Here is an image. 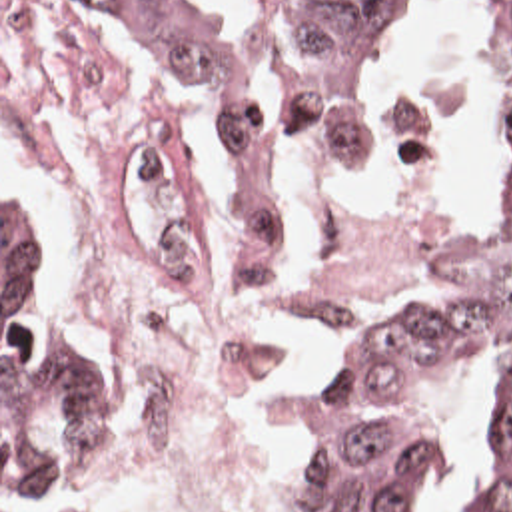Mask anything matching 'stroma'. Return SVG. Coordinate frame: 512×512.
<instances>
[{
    "label": "stroma",
    "instance_id": "1",
    "mask_svg": "<svg viewBox=\"0 0 512 512\" xmlns=\"http://www.w3.org/2000/svg\"><path fill=\"white\" fill-rule=\"evenodd\" d=\"M94 21L118 47L132 77L166 109L178 183L192 209L202 275L206 283L232 291H246L266 277L276 247L294 229L313 215L345 205H425L457 211L463 245L447 255L415 267L399 269L383 299L357 317L325 351L311 375L300 405L294 458L310 428L317 401L343 349L369 325L379 309L391 301L411 295L435 281L449 265L485 249L489 229V207L467 179L463 167L455 163H429L413 167L391 179L331 187L300 203L286 219L274 225L272 245L264 273H240L236 259V233L230 221V199L222 187V163L216 153L210 129L190 101L180 93L172 75L156 69L134 45L122 39L100 15L88 9ZM2 189L10 191L18 203L30 211L40 255L52 289V323L58 333L70 337L92 353L108 373L122 401V450L120 454L76 480L58 494H2ZM485 434V389L473 379L471 411L429 466L417 494L405 512H455L473 474L477 450ZM138 438V395L132 363L116 339L100 327L84 309L66 271L62 249L52 235L36 197L26 179L20 157L2 133V0H0V512H68L92 498L108 492L132 466Z\"/></svg>",
    "mask_w": 512,
    "mask_h": 512
}]
</instances>
